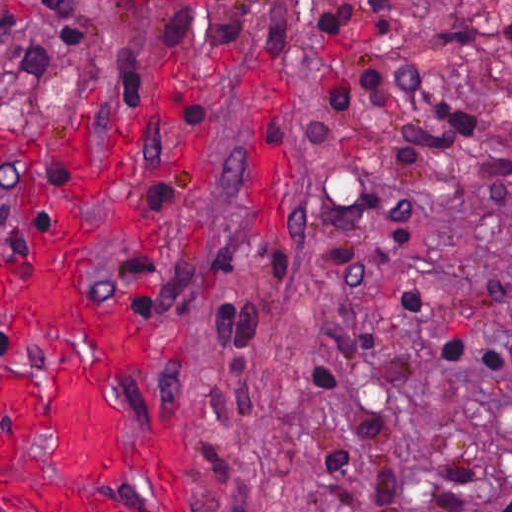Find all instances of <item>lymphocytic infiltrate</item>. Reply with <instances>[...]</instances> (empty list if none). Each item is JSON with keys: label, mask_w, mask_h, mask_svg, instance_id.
I'll use <instances>...</instances> for the list:
<instances>
[{"label": "lymphocytic infiltrate", "mask_w": 512, "mask_h": 512, "mask_svg": "<svg viewBox=\"0 0 512 512\" xmlns=\"http://www.w3.org/2000/svg\"><path fill=\"white\" fill-rule=\"evenodd\" d=\"M396 0H306L309 34L362 132L308 128L324 173L328 264L347 277L367 271L375 224L403 226L410 172L447 178L512 223V153L472 109L409 77L394 45ZM406 352L481 376L506 353L497 330L444 313L407 288L387 292L366 320L346 326L312 362L324 427L322 512H404L401 481L381 439ZM479 471L462 449L438 458L431 512H512V498L481 501Z\"/></svg>", "instance_id": "obj_1"}]
</instances>
